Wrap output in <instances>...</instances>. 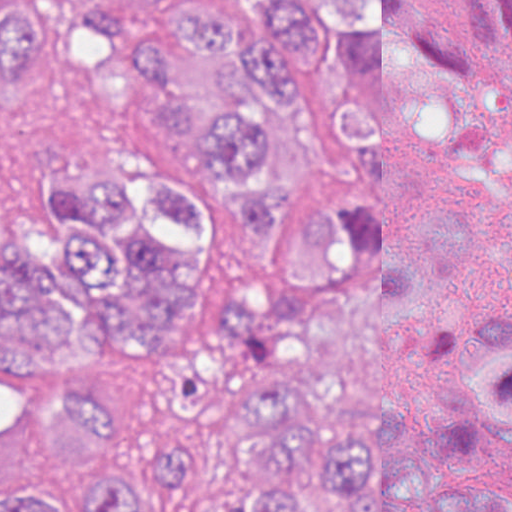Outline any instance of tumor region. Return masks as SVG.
Returning <instances> with one entry per match:
<instances>
[{"label":"tumor region","mask_w":512,"mask_h":512,"mask_svg":"<svg viewBox=\"0 0 512 512\" xmlns=\"http://www.w3.org/2000/svg\"><path fill=\"white\" fill-rule=\"evenodd\" d=\"M476 97L414 0H0V512H512Z\"/></svg>","instance_id":"e687c5a6"}]
</instances>
